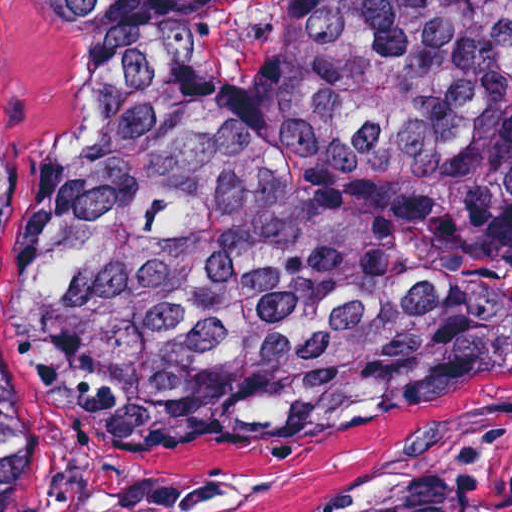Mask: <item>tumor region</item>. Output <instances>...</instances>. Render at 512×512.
<instances>
[{
    "label": "tumor region",
    "instance_id": "e687c5a6",
    "mask_svg": "<svg viewBox=\"0 0 512 512\" xmlns=\"http://www.w3.org/2000/svg\"><path fill=\"white\" fill-rule=\"evenodd\" d=\"M71 76L23 251L0 108V512L17 352L143 446L232 457L512 349V0H43ZM438 512H512V408Z\"/></svg>",
    "mask_w": 512,
    "mask_h": 512
}]
</instances>
